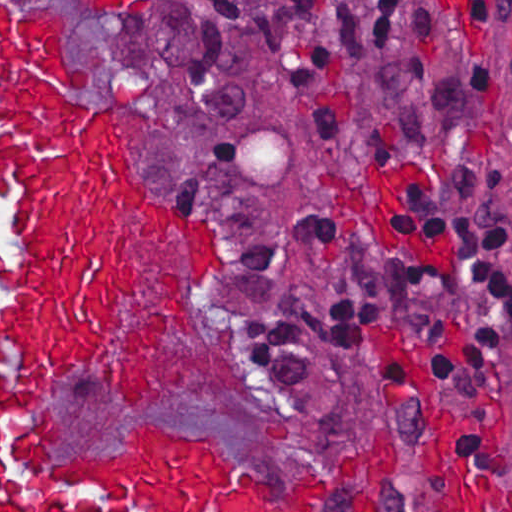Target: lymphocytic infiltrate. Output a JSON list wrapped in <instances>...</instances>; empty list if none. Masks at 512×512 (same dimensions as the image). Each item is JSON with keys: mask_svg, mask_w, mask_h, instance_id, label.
Here are the masks:
<instances>
[{"mask_svg": "<svg viewBox=\"0 0 512 512\" xmlns=\"http://www.w3.org/2000/svg\"><path fill=\"white\" fill-rule=\"evenodd\" d=\"M255 1L264 47L286 96L317 142L339 138L352 108L355 67L394 42L409 0H196L177 68L178 94L193 120H222L244 98L245 13ZM450 1L459 52L493 24L512 26V0ZM413 53L415 69L394 80V116L410 147H436L440 165L434 178L402 187L393 203L392 233L402 252L390 301L404 331L423 339L465 305L476 317L474 339L447 350L437 363L441 392L462 415L468 388L496 369L512 345V220L498 210L507 168L473 150L502 84L496 67L483 60L446 63L439 21L423 11L413 21ZM320 206L297 215L290 233L303 253L338 258L315 242ZM230 241L237 250V282L279 264L268 242ZM365 287L332 301L318 313V324L336 348L367 362L360 336ZM237 309L264 376L289 409L313 381L299 317L262 311L238 294Z\"/></svg>", "mask_w": 512, "mask_h": 512, "instance_id": "obj_1", "label": "lymphocytic infiltrate"}]
</instances>
